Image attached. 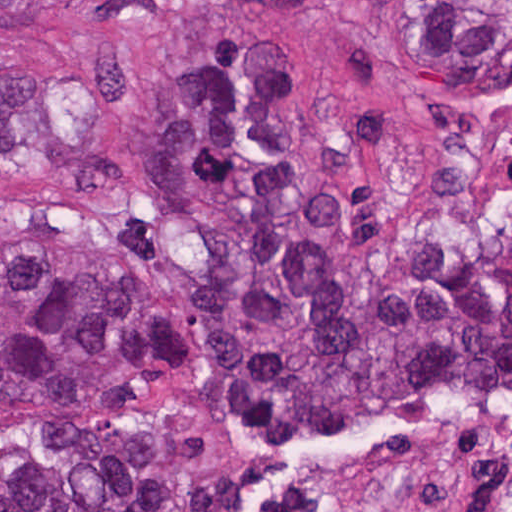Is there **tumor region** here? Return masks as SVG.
Here are the masks:
<instances>
[{
  "label": "tumor region",
  "instance_id": "obj_1",
  "mask_svg": "<svg viewBox=\"0 0 512 512\" xmlns=\"http://www.w3.org/2000/svg\"><path fill=\"white\" fill-rule=\"evenodd\" d=\"M76 1L0 0V26ZM364 1L405 19L431 97L512 89V0ZM0 181L120 195L93 238L0 268V512H246L234 472L182 480L141 411L189 380L131 252L144 214L192 241L196 381L265 464L512 382V242L479 227L436 238L372 286L349 213L311 176L305 102L276 44L181 42L130 138L92 143L38 72L0 67Z\"/></svg>",
  "mask_w": 512,
  "mask_h": 512
}]
</instances>
